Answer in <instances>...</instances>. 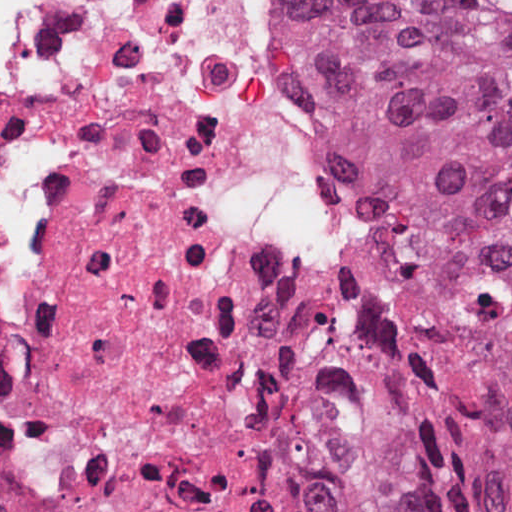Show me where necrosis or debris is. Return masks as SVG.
Listing matches in <instances>:
<instances>
[{"label": "necrosis or debris", "instance_id": "obj_1", "mask_svg": "<svg viewBox=\"0 0 512 512\" xmlns=\"http://www.w3.org/2000/svg\"><path fill=\"white\" fill-rule=\"evenodd\" d=\"M373 268L278 0H0V512H346L282 370Z\"/></svg>", "mask_w": 512, "mask_h": 512}]
</instances>
